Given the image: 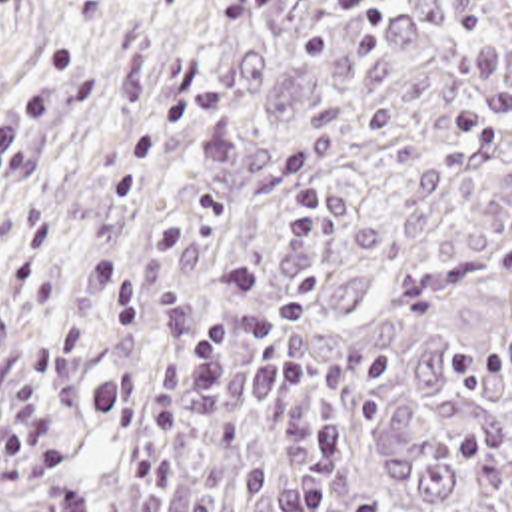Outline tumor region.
Returning a JSON list of instances; mask_svg holds the SVG:
<instances>
[{
  "mask_svg": "<svg viewBox=\"0 0 512 512\" xmlns=\"http://www.w3.org/2000/svg\"><path fill=\"white\" fill-rule=\"evenodd\" d=\"M0 512H512V0H151L0 198Z\"/></svg>",
  "mask_w": 512,
  "mask_h": 512,
  "instance_id": "e687c5a6",
  "label": "tumor region"
}]
</instances>
